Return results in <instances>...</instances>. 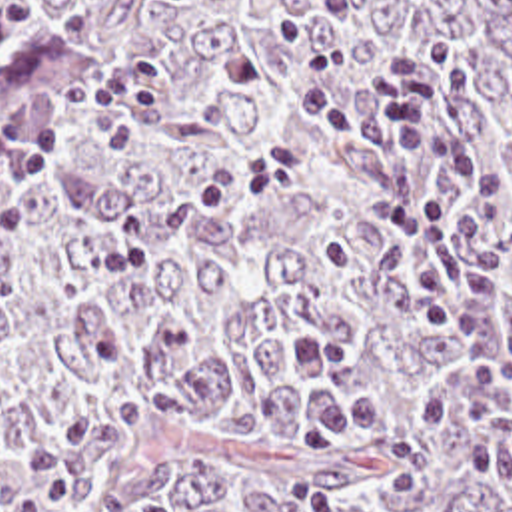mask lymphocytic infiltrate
I'll return each instance as SVG.
<instances>
[{
	"label": "lymphocytic infiltrate",
	"mask_w": 512,
	"mask_h": 512,
	"mask_svg": "<svg viewBox=\"0 0 512 512\" xmlns=\"http://www.w3.org/2000/svg\"><path fill=\"white\" fill-rule=\"evenodd\" d=\"M313 2L337 34L275 24L295 62L289 96L319 128L375 150L379 174L367 218L397 240L423 320L455 336L457 376L421 398L419 416L427 428L461 436L477 468L512 462V326L501 328L499 314L509 258L491 226L509 180L471 148L451 146L429 166L419 162L421 144L443 130L451 100L475 88L473 66L451 40L427 38L391 52L351 102L337 90V76L363 46V12L357 0ZM33 470L55 512H77L91 486L87 456L49 440Z\"/></svg>",
	"instance_id": "obj_1"
}]
</instances>
